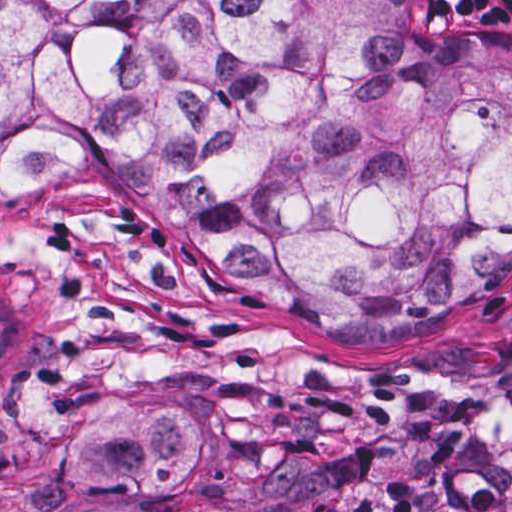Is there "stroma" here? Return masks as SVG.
<instances>
[{
  "instance_id": "35a3bbf8",
  "label": "stroma",
  "mask_w": 512,
  "mask_h": 512,
  "mask_svg": "<svg viewBox=\"0 0 512 512\" xmlns=\"http://www.w3.org/2000/svg\"><path fill=\"white\" fill-rule=\"evenodd\" d=\"M512 44V0H418ZM1 253L43 331L1 368ZM206 424L205 485L166 500L49 491L99 396ZM0 512H512V281L398 334L329 336L215 275L100 165L1 187Z\"/></svg>"
}]
</instances>
